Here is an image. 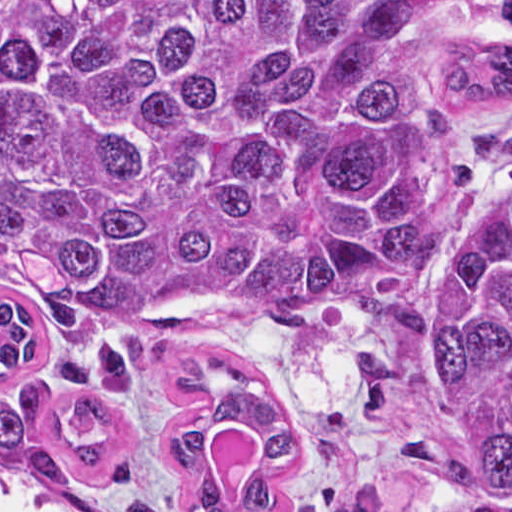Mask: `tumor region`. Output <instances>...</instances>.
Returning a JSON list of instances; mask_svg holds the SVG:
<instances>
[{
    "instance_id": "tumor-region-1",
    "label": "tumor region",
    "mask_w": 512,
    "mask_h": 512,
    "mask_svg": "<svg viewBox=\"0 0 512 512\" xmlns=\"http://www.w3.org/2000/svg\"><path fill=\"white\" fill-rule=\"evenodd\" d=\"M411 10L375 0H0V261L44 313L52 357L96 442L66 432L49 386L0 392V469L71 485L104 474L122 426L103 397L138 392L151 342L194 314L366 318L388 343L348 381L356 419L386 411L431 343L436 312L409 292L444 261L479 172L512 161V128L462 130L512 98V49L454 41L427 112L407 65ZM493 32L512 34V0ZM439 349L465 462L423 436L400 444L455 486L438 512H512V182L483 211L439 288ZM38 353V311L0 301V370ZM173 386L206 397L163 430L188 476L216 426L268 432L243 491L197 475L193 512H261L291 463L273 381L201 352ZM386 486L324 487L321 512H376ZM130 512H159L147 501Z\"/></svg>"
}]
</instances>
